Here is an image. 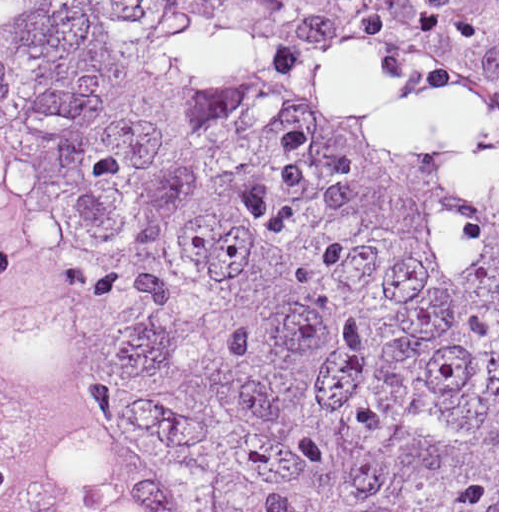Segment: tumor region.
<instances>
[{
    "label": "tumor region",
    "mask_w": 512,
    "mask_h": 512,
    "mask_svg": "<svg viewBox=\"0 0 512 512\" xmlns=\"http://www.w3.org/2000/svg\"><path fill=\"white\" fill-rule=\"evenodd\" d=\"M0 291L113 385L152 512H497V128L301 0H0Z\"/></svg>",
    "instance_id": "1"
}]
</instances>
